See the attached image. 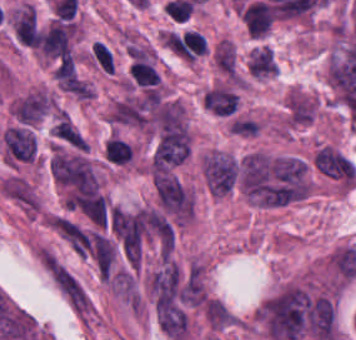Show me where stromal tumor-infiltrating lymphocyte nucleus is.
Returning <instances> with one entry per match:
<instances>
[{
  "mask_svg": "<svg viewBox=\"0 0 356 340\" xmlns=\"http://www.w3.org/2000/svg\"><path fill=\"white\" fill-rule=\"evenodd\" d=\"M249 34H263L267 32L273 18L272 7L263 2H255L247 6L241 13Z\"/></svg>",
  "mask_w": 356,
  "mask_h": 340,
  "instance_id": "bc302bb0",
  "label": "stromal tumor-infiltrating lymphocyte nucleus"
},
{
  "mask_svg": "<svg viewBox=\"0 0 356 340\" xmlns=\"http://www.w3.org/2000/svg\"><path fill=\"white\" fill-rule=\"evenodd\" d=\"M104 156L112 163H125L129 157V150L125 143L118 138H110L105 143Z\"/></svg>",
  "mask_w": 356,
  "mask_h": 340,
  "instance_id": "52c7bb5b",
  "label": "stromal tumor-infiltrating lymphocyte nucleus"
}]
</instances>
